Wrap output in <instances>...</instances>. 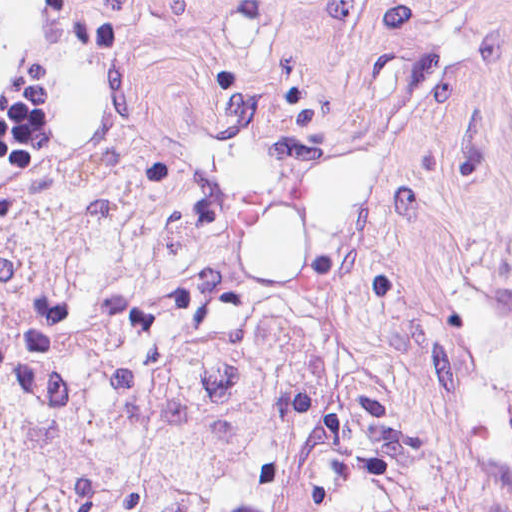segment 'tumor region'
I'll return each mask as SVG.
<instances>
[{"label": "tumor region", "mask_w": 512, "mask_h": 512, "mask_svg": "<svg viewBox=\"0 0 512 512\" xmlns=\"http://www.w3.org/2000/svg\"><path fill=\"white\" fill-rule=\"evenodd\" d=\"M132 45V1H116Z\"/></svg>", "instance_id": "obj_1"}]
</instances>
